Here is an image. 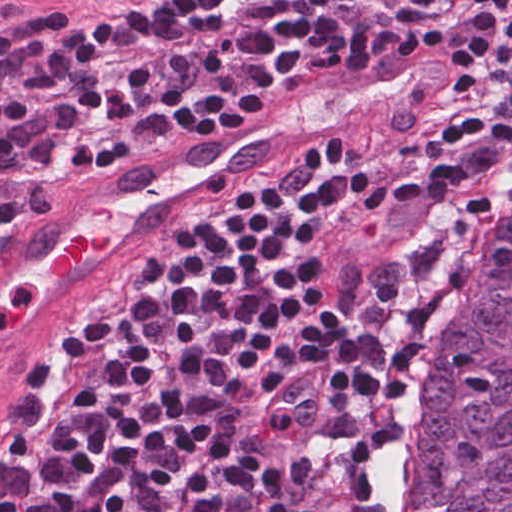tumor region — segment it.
Listing matches in <instances>:
<instances>
[{
	"label": "tumor region",
	"instance_id": "obj_1",
	"mask_svg": "<svg viewBox=\"0 0 512 512\" xmlns=\"http://www.w3.org/2000/svg\"><path fill=\"white\" fill-rule=\"evenodd\" d=\"M8 479L9 485L11 486L14 496H15V503H16V510L17 512H31L30 503L24 496V494L21 492L19 487L16 485L14 481Z\"/></svg>",
	"mask_w": 512,
	"mask_h": 512
}]
</instances>
